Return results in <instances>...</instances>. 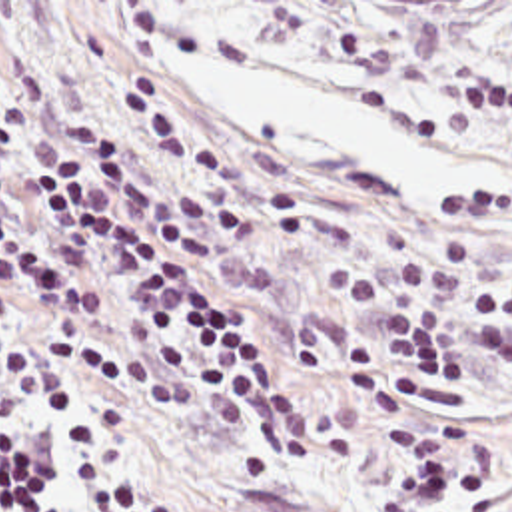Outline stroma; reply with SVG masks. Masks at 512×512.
Masks as SVG:
<instances>
[{"label": "stroma", "mask_w": 512, "mask_h": 512, "mask_svg": "<svg viewBox=\"0 0 512 512\" xmlns=\"http://www.w3.org/2000/svg\"><path fill=\"white\" fill-rule=\"evenodd\" d=\"M221 66H251L345 94L424 144L494 176L464 198H420L396 176L331 160L295 132L225 118L207 94ZM49 112L115 140L149 182L187 186L221 250L213 291L235 305L295 385L317 427L311 457L275 459L221 431L167 375L123 365L101 383L109 483L101 512L149 499L165 512H388L392 421L365 411L355 343L376 315L333 287L339 264L376 279L444 230L478 262L430 299L458 301L468 345L492 277L512 272V32L39 80ZM474 383L428 401L464 427L456 509L512 512V377L478 361Z\"/></svg>", "instance_id": "stroma-1"}]
</instances>
